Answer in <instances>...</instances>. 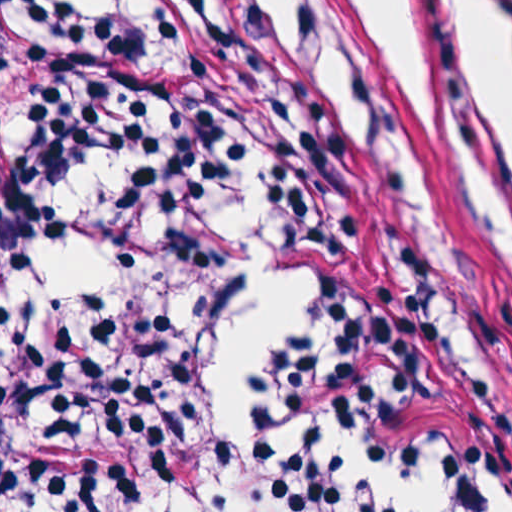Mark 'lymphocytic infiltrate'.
I'll return each instance as SVG.
<instances>
[{
	"mask_svg": "<svg viewBox=\"0 0 512 512\" xmlns=\"http://www.w3.org/2000/svg\"><path fill=\"white\" fill-rule=\"evenodd\" d=\"M121 170L115 261L211 254L245 170L314 297L273 363L266 430H347L406 469L512 509V425L395 272L353 154L341 51L320 0H1V335L5 500L151 512L182 486L201 382L239 293L174 287L46 303L92 158ZM248 512H396L346 476L246 457Z\"/></svg>",
	"mask_w": 512,
	"mask_h": 512,
	"instance_id": "obj_1",
	"label": "lymphocytic infiltrate"
}]
</instances>
